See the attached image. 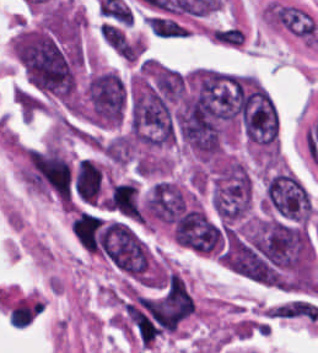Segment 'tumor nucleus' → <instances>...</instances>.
Returning <instances> with one entry per match:
<instances>
[{"label":"tumor nucleus","mask_w":318,"mask_h":353,"mask_svg":"<svg viewBox=\"0 0 318 353\" xmlns=\"http://www.w3.org/2000/svg\"><path fill=\"white\" fill-rule=\"evenodd\" d=\"M260 204L275 218L292 224H306V191L288 171H269L264 177Z\"/></svg>","instance_id":"obj_1"}]
</instances>
